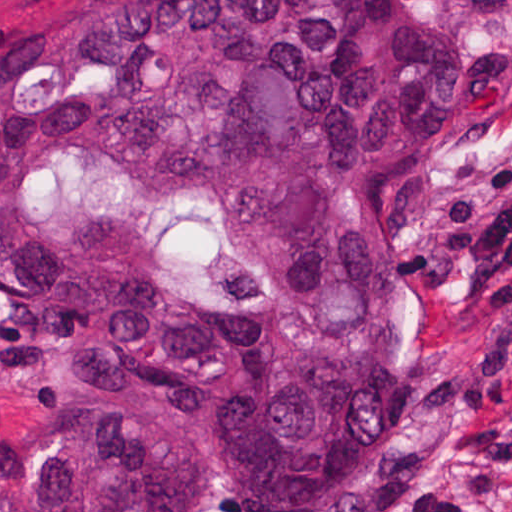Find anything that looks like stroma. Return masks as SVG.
<instances>
[{"instance_id":"obj_1","label":"stroma","mask_w":512,"mask_h":512,"mask_svg":"<svg viewBox=\"0 0 512 512\" xmlns=\"http://www.w3.org/2000/svg\"><path fill=\"white\" fill-rule=\"evenodd\" d=\"M119 0H0V36ZM447 19L512 39V0H410ZM512 188V85L488 108L457 118L404 179L401 256L407 274V341L394 369L404 416L382 463L344 512H377L379 492L422 487L459 512H512V412L471 416L460 402L481 288L468 265L440 250L437 223L455 204L498 209ZM0 307V347L14 322ZM37 404L0 380V451L32 447Z\"/></svg>"}]
</instances>
